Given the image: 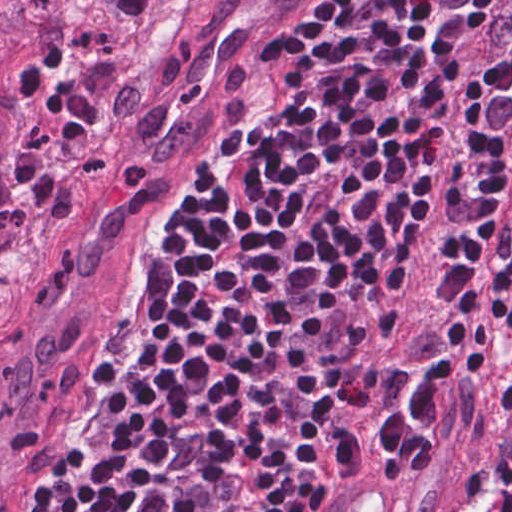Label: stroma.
I'll use <instances>...</instances> for the list:
<instances>
[{
    "label": "stroma",
    "mask_w": 512,
    "mask_h": 512,
    "mask_svg": "<svg viewBox=\"0 0 512 512\" xmlns=\"http://www.w3.org/2000/svg\"><path fill=\"white\" fill-rule=\"evenodd\" d=\"M308 285L348 287L358 292L371 311V334L399 313L356 280L265 285L255 288L249 296ZM395 342L369 350L363 390L348 413L346 440L331 468L324 512H330L352 478L354 481L361 472L369 471H376L397 494L400 512H456L470 493L487 482L496 460L512 445V404L506 400L511 352L502 368L462 403L456 426L441 454L421 464L411 461L403 470L387 468L362 408L393 366L397 356Z\"/></svg>",
    "instance_id": "stroma-1"
}]
</instances>
